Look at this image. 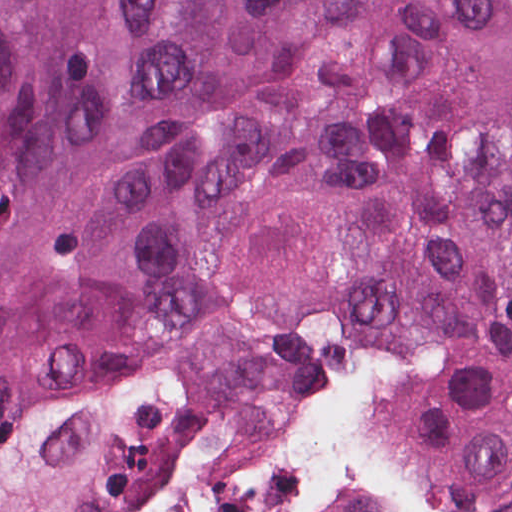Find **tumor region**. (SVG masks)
<instances>
[{
	"label": "tumor region",
	"mask_w": 512,
	"mask_h": 512,
	"mask_svg": "<svg viewBox=\"0 0 512 512\" xmlns=\"http://www.w3.org/2000/svg\"><path fill=\"white\" fill-rule=\"evenodd\" d=\"M403 333L512 500V0H0V512H118Z\"/></svg>",
	"instance_id": "1"
}]
</instances>
